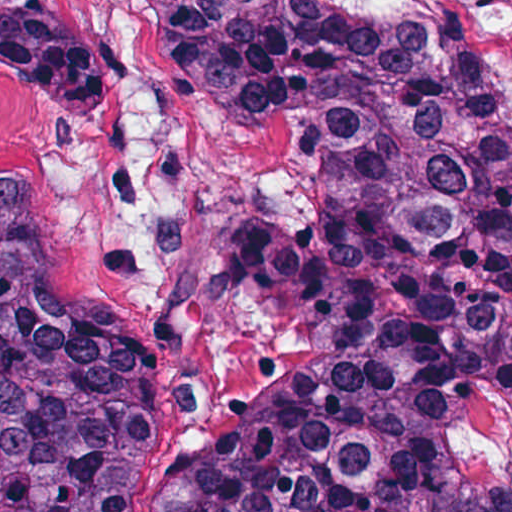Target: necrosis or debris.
I'll use <instances>...</instances> for the list:
<instances>
[{"instance_id": "obj_1", "label": "necrosis or debris", "mask_w": 512, "mask_h": 512, "mask_svg": "<svg viewBox=\"0 0 512 512\" xmlns=\"http://www.w3.org/2000/svg\"><path fill=\"white\" fill-rule=\"evenodd\" d=\"M421 35L458 28L485 59L512 102V0H346Z\"/></svg>"}]
</instances>
